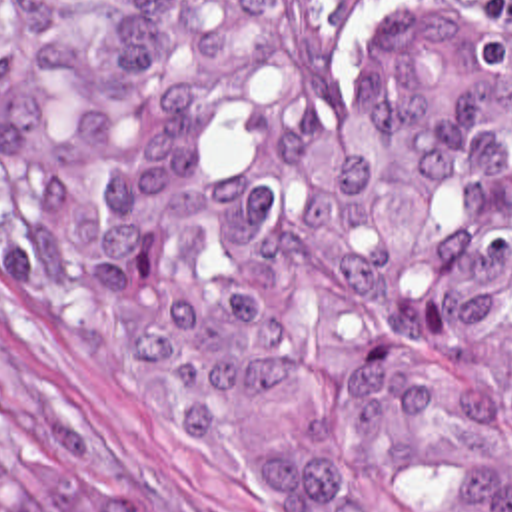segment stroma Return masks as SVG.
<instances>
[{
    "mask_svg": "<svg viewBox=\"0 0 512 512\" xmlns=\"http://www.w3.org/2000/svg\"><path fill=\"white\" fill-rule=\"evenodd\" d=\"M430 0H392L364 44L352 90L378 94L366 72L376 38ZM0 390L20 422L84 483L152 512H304L208 449L160 426L124 382L58 350L0 274Z\"/></svg>",
    "mask_w": 512,
    "mask_h": 512,
    "instance_id": "1",
    "label": "stroma"
}]
</instances>
